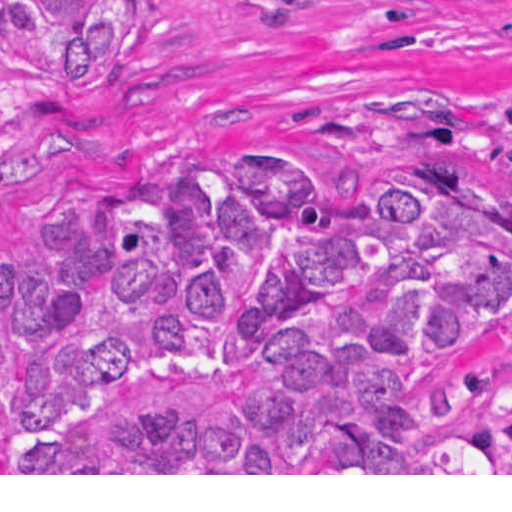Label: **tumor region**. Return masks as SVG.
Here are the masks:
<instances>
[{
    "instance_id": "tumor-region-1",
    "label": "tumor region",
    "mask_w": 512,
    "mask_h": 512,
    "mask_svg": "<svg viewBox=\"0 0 512 512\" xmlns=\"http://www.w3.org/2000/svg\"><path fill=\"white\" fill-rule=\"evenodd\" d=\"M157 28V0H0V75L98 103ZM508 302L512 186L162 163L57 194L0 261V436L19 473H512Z\"/></svg>"
}]
</instances>
